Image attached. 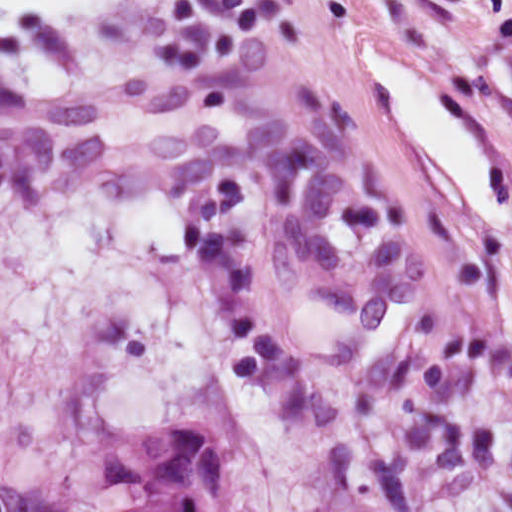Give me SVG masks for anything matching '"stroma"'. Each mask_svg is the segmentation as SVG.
Here are the masks:
<instances>
[{"instance_id": "1", "label": "stroma", "mask_w": 512, "mask_h": 512, "mask_svg": "<svg viewBox=\"0 0 512 512\" xmlns=\"http://www.w3.org/2000/svg\"><path fill=\"white\" fill-rule=\"evenodd\" d=\"M0 47V512L206 425L256 512H512V0H92Z\"/></svg>"}]
</instances>
